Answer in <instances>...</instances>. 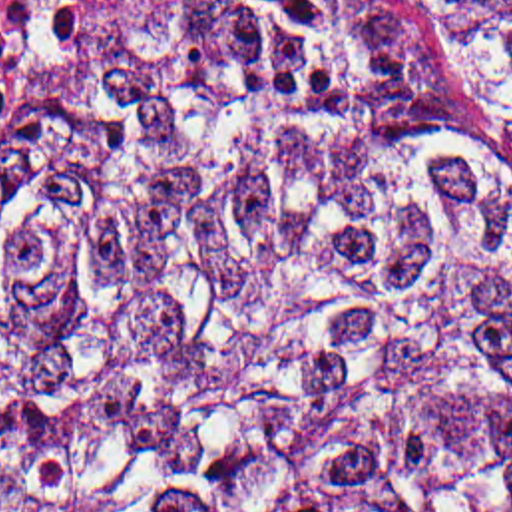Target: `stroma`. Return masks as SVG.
<instances>
[{
	"label": "stroma",
	"mask_w": 512,
	"mask_h": 512,
	"mask_svg": "<svg viewBox=\"0 0 512 512\" xmlns=\"http://www.w3.org/2000/svg\"><path fill=\"white\" fill-rule=\"evenodd\" d=\"M123 1H125V0L109 1V3H107V5H105V7H103V9H101V11H99V13H95V15H91V17H87V19H85V21H83V23H81V25H79V27H77V29H75V31H71V33H69V35H67V39H65V41H69V39H71V37H73V35H77V33H79V31H83V29H85V27H87V25H91V23H93V21H97V19H99V17H103V15H105V13H109V11H111V9H113V7H117V5H119V3H123ZM59 49H61V47H57V49H55V51H53V53H51V55H49V57H47V59H43V61H41V63H39V65H37V67H35V69H33V71H29V73H25V75H23V77H21V79H19V81H17V83H15V85H13V87H9V89H7V91H5V93H1V95H0V117H1V115H3V113H5V111H7V109H11V107H13V105H15V103H17V101H19V99H21V95H23V93H25V91H27V89H29V87H31V85H33V83H35V79H37V77H39V75H41V73H43V71H45V67H47V65H49V63H51V59H53V57H55V53H57V51H59Z\"/></svg>",
	"instance_id": "obj_1"
}]
</instances>
